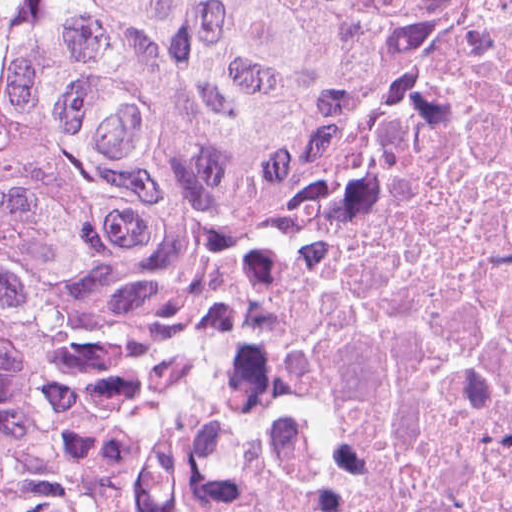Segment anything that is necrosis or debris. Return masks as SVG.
<instances>
[{"label":"necrosis or debris","instance_id":"obj_1","mask_svg":"<svg viewBox=\"0 0 512 512\" xmlns=\"http://www.w3.org/2000/svg\"><path fill=\"white\" fill-rule=\"evenodd\" d=\"M165 512H512V0H430L396 148Z\"/></svg>","mask_w":512,"mask_h":512}]
</instances>
